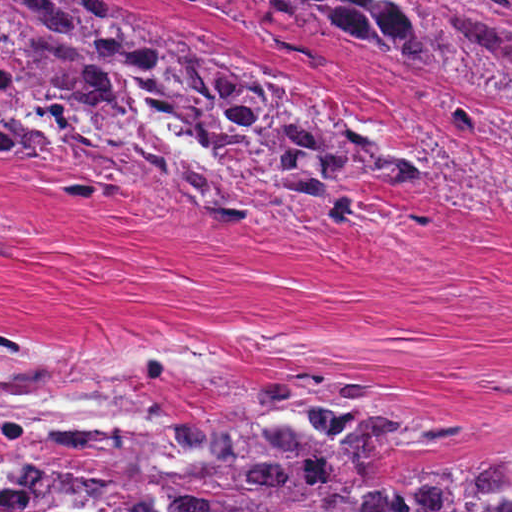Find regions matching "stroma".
<instances>
[{"label":"stroma","instance_id":"1","mask_svg":"<svg viewBox=\"0 0 512 512\" xmlns=\"http://www.w3.org/2000/svg\"><path fill=\"white\" fill-rule=\"evenodd\" d=\"M106 1L129 26H174L198 53L341 98L417 180L360 185L350 224L314 242L239 212L191 219L143 185L75 194L50 145L3 147L0 318L40 339L153 337L205 384L350 367L385 380L369 406L506 416L482 452L410 447L397 464L512 445V105L276 4Z\"/></svg>","mask_w":512,"mask_h":512}]
</instances>
